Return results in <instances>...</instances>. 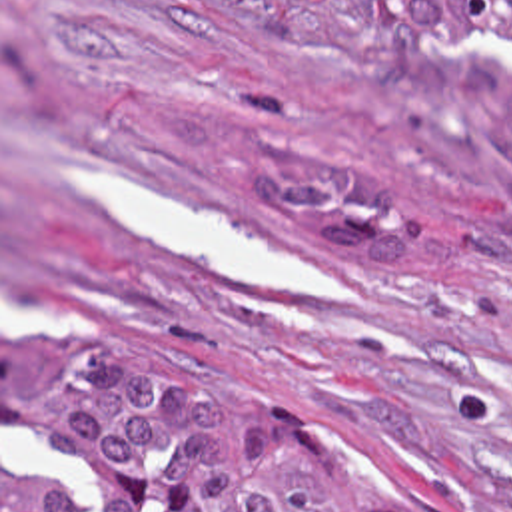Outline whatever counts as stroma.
<instances>
[{
  "label": "stroma",
  "mask_w": 512,
  "mask_h": 512,
  "mask_svg": "<svg viewBox=\"0 0 512 512\" xmlns=\"http://www.w3.org/2000/svg\"><path fill=\"white\" fill-rule=\"evenodd\" d=\"M399 37L463 35L373 0H0V151L34 123L146 159L341 285H234L86 211L76 289L102 339L144 327L206 355L331 433L399 512H512V211L351 81L355 49ZM92 345L0 349V512L2 417L26 481L92 512L52 473V383Z\"/></svg>",
  "instance_id": "1"
}]
</instances>
